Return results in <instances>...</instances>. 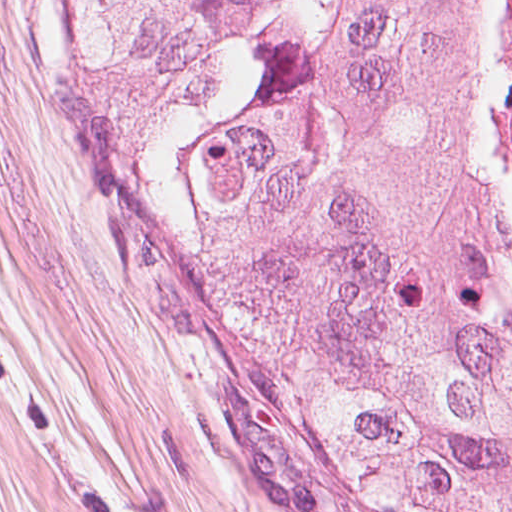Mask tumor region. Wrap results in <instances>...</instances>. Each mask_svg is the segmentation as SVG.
<instances>
[{
    "mask_svg": "<svg viewBox=\"0 0 512 512\" xmlns=\"http://www.w3.org/2000/svg\"><path fill=\"white\" fill-rule=\"evenodd\" d=\"M200 333L327 512H512V232L471 0H77Z\"/></svg>",
    "mask_w": 512,
    "mask_h": 512,
    "instance_id": "obj_1",
    "label": "tumor region"
}]
</instances>
